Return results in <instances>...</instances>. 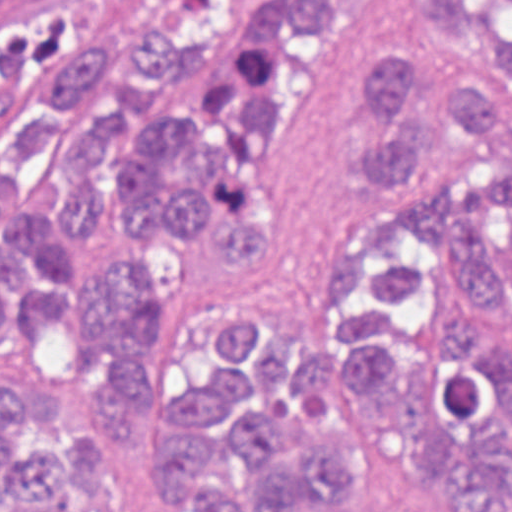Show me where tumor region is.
I'll return each mask as SVG.
<instances>
[{
  "mask_svg": "<svg viewBox=\"0 0 512 512\" xmlns=\"http://www.w3.org/2000/svg\"><path fill=\"white\" fill-rule=\"evenodd\" d=\"M110 0H0V95L43 85L9 170L39 159L68 103L107 73ZM431 48L365 61L350 148L365 216L308 304L253 329L225 319L149 384L139 335L163 276L149 248L210 230L228 259L274 242L259 158L292 81L289 43L344 0H276L249 25L198 123L144 126L166 85L214 61L232 11L201 33L156 21L130 39L115 113L60 142L78 188L0 208V320L76 318L85 365L117 386L0 383V512H512V164L474 134L502 125L512 0H408ZM4 174H0L2 177Z\"/></svg>",
  "mask_w": 512,
  "mask_h": 512,
  "instance_id": "obj_1",
  "label": "tumor region"
}]
</instances>
